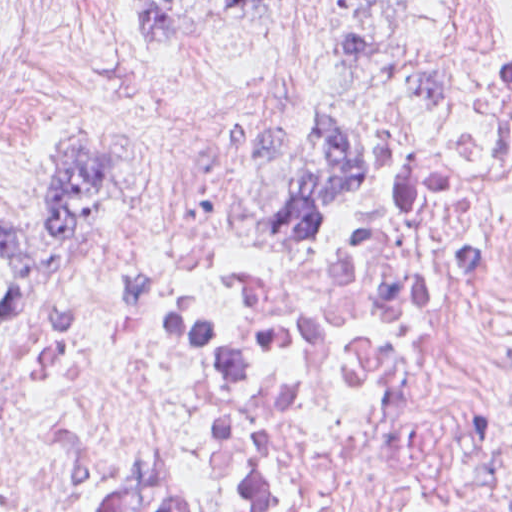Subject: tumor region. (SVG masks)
Listing matches in <instances>:
<instances>
[{
	"mask_svg": "<svg viewBox=\"0 0 512 512\" xmlns=\"http://www.w3.org/2000/svg\"><path fill=\"white\" fill-rule=\"evenodd\" d=\"M265 0H128V26L136 49L153 65L181 58ZM362 0H351L344 23L320 60L305 93L331 64L365 62L375 49L361 31ZM304 93V95H305ZM311 182L283 198L268 217L273 233L321 252L339 239L324 230L326 209L352 200L365 173L360 140L333 115L308 132ZM138 181L111 149L74 135L55 154L49 203L0 209L2 301L7 314L25 309L28 293L59 282L69 250L112 232L137 204ZM263 267H271L248 254Z\"/></svg>",
	"mask_w": 512,
	"mask_h": 512,
	"instance_id": "1",
	"label": "tumor region"
}]
</instances>
